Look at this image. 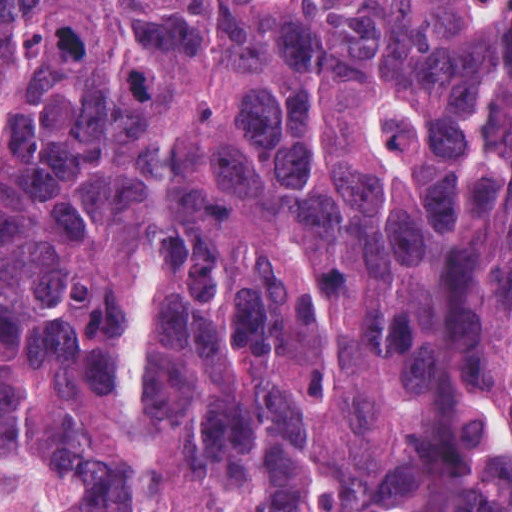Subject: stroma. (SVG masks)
<instances>
[{
	"mask_svg": "<svg viewBox=\"0 0 512 512\" xmlns=\"http://www.w3.org/2000/svg\"><path fill=\"white\" fill-rule=\"evenodd\" d=\"M77 481L70 463L58 471L0 460V512H76Z\"/></svg>",
	"mask_w": 512,
	"mask_h": 512,
	"instance_id": "1",
	"label": "stroma"
}]
</instances>
